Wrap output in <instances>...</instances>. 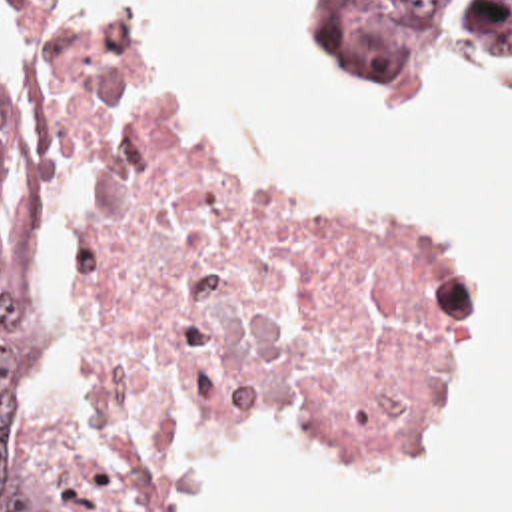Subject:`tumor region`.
<instances>
[{
    "label": "tumor region",
    "instance_id": "obj_1",
    "mask_svg": "<svg viewBox=\"0 0 512 512\" xmlns=\"http://www.w3.org/2000/svg\"><path fill=\"white\" fill-rule=\"evenodd\" d=\"M452 0H332L318 11L342 55L364 81L414 67ZM490 65L512 67V0H478L470 27ZM9 99L0 85V169L9 151ZM35 273V213L21 201L0 245V512H53L39 476L19 454L15 385L25 363L27 297Z\"/></svg>",
    "mask_w": 512,
    "mask_h": 512
}]
</instances>
